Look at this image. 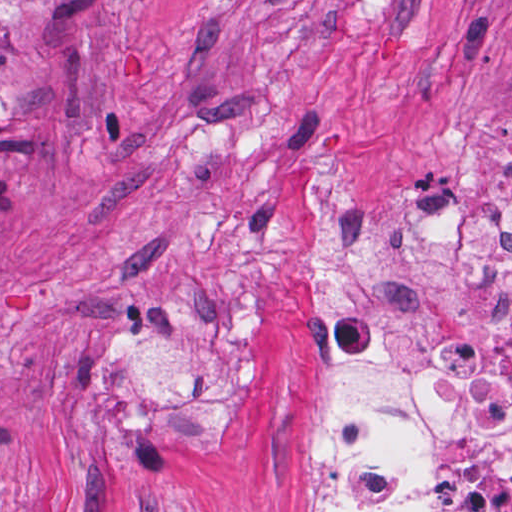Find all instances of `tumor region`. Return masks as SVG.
<instances>
[{"label": "tumor region", "instance_id": "obj_1", "mask_svg": "<svg viewBox=\"0 0 512 512\" xmlns=\"http://www.w3.org/2000/svg\"><path fill=\"white\" fill-rule=\"evenodd\" d=\"M51 0H0V93L25 77L26 53L33 34L46 21L34 20V9Z\"/></svg>", "mask_w": 512, "mask_h": 512}]
</instances>
